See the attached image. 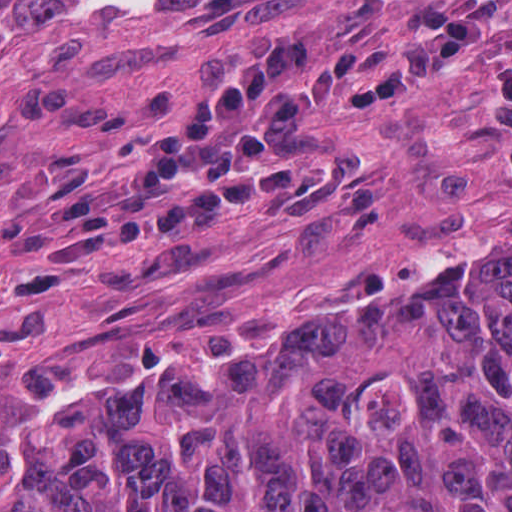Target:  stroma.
Returning <instances> with one entry per match:
<instances>
[{
	"instance_id": "1",
	"label": "stroma",
	"mask_w": 512,
	"mask_h": 512,
	"mask_svg": "<svg viewBox=\"0 0 512 512\" xmlns=\"http://www.w3.org/2000/svg\"><path fill=\"white\" fill-rule=\"evenodd\" d=\"M0 1V410L423 351L512 281V0Z\"/></svg>"
}]
</instances>
